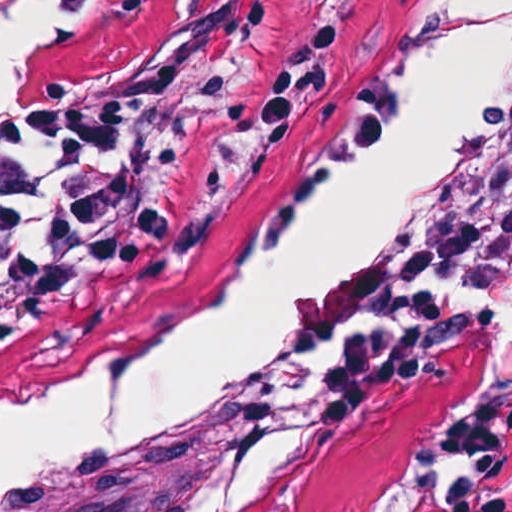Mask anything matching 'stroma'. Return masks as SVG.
I'll list each match as a JSON object with an SVG mask.
<instances>
[{"instance_id":"35a3bbf8","label":"stroma","mask_w":512,"mask_h":512,"mask_svg":"<svg viewBox=\"0 0 512 512\" xmlns=\"http://www.w3.org/2000/svg\"><path fill=\"white\" fill-rule=\"evenodd\" d=\"M14 1L0 0V46ZM425 1L95 0L18 107H105L130 126L112 165L146 181L141 225L124 265L0 353V418L110 359L256 242L331 111ZM479 391L512 421V280L446 323H395L369 282L359 373L275 512H430L432 424ZM191 488L128 465L26 512H182Z\"/></svg>"}]
</instances>
